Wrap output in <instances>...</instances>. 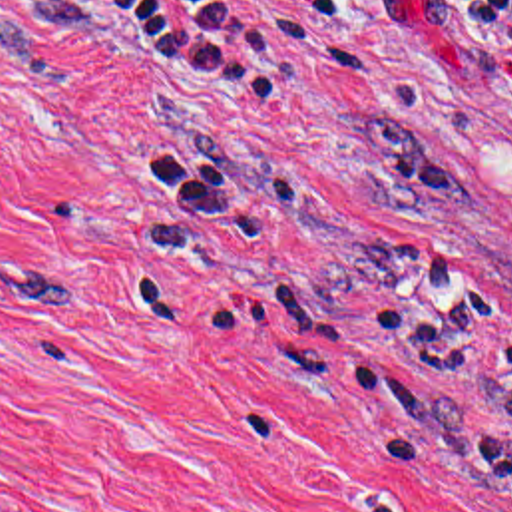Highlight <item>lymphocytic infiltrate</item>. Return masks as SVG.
I'll list each match as a JSON object with an SVG mask.
<instances>
[{"instance_id":"f902f5d3","label":"lymphocytic infiltrate","mask_w":512,"mask_h":512,"mask_svg":"<svg viewBox=\"0 0 512 512\" xmlns=\"http://www.w3.org/2000/svg\"><path fill=\"white\" fill-rule=\"evenodd\" d=\"M444 3L474 55L501 75L512 91V0ZM352 286L372 310L380 342L414 367L452 369L474 363L489 336L503 326L464 258L436 252L398 256L388 240H368L356 252ZM173 306L235 346L286 351L294 344H338V324L320 298H290L266 284L248 286L245 294L201 310ZM499 365L512 375V346ZM324 387L344 397L386 403L410 415L412 435L382 449L390 459L426 461V423L448 391L410 385L374 369L340 373ZM479 443L483 463L474 481L497 483L512 491V391L495 405Z\"/></svg>"}]
</instances>
